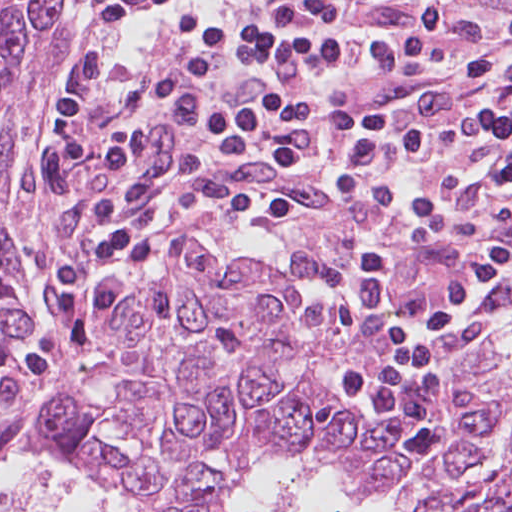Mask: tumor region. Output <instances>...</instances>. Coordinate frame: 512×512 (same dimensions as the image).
<instances>
[{"label": "tumor region", "instance_id": "1", "mask_svg": "<svg viewBox=\"0 0 512 512\" xmlns=\"http://www.w3.org/2000/svg\"><path fill=\"white\" fill-rule=\"evenodd\" d=\"M376 501L404 512H512V456Z\"/></svg>", "mask_w": 512, "mask_h": 512}]
</instances>
